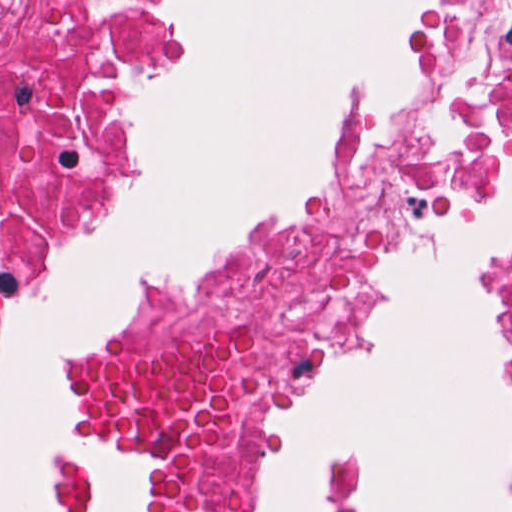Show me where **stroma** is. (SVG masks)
<instances>
[{
	"instance_id": "obj_1",
	"label": "stroma",
	"mask_w": 512,
	"mask_h": 512,
	"mask_svg": "<svg viewBox=\"0 0 512 512\" xmlns=\"http://www.w3.org/2000/svg\"><path fill=\"white\" fill-rule=\"evenodd\" d=\"M451 0H420L405 29L409 79L398 97L385 86H364L333 117L321 161L329 184L290 212L252 223L222 246L208 265L188 275H153L115 299L94 329L71 339L61 354L57 394L68 413V434L49 475L57 512H95L103 492L83 453H117L140 461V482L125 512H145L163 479V460L138 435H118L87 413L89 374L109 342L142 312L192 281L310 219L337 198L348 182L357 136L369 119L404 108L420 97L428 80L434 40ZM182 34L145 70L130 102L160 72L182 62ZM129 102V103H130ZM512 141V125L491 136L472 174H449L426 206L381 246L317 314L297 342L267 361L251 377L223 491V512H262L273 472V435L298 414L317 383L345 366L375 340L388 312L395 260L413 252L434 229L437 211L460 201L493 199L506 192L497 145ZM135 166V141L128 108L98 176L83 186L72 205L40 230L0 273V358L8 334L24 319V294L44 283L88 234L124 206ZM496 294L501 342L512 392V259L485 276Z\"/></svg>"
}]
</instances>
